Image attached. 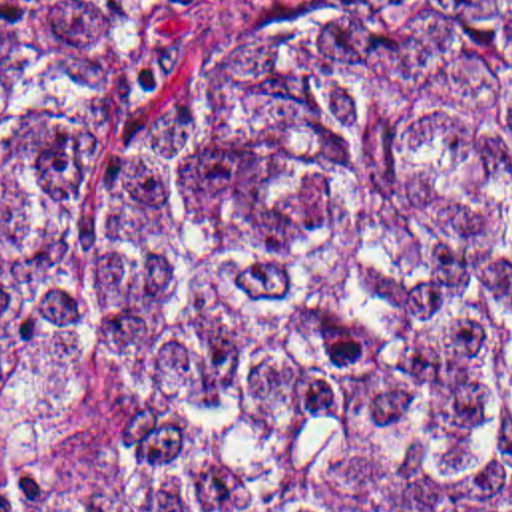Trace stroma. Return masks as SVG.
Returning <instances> with one entry per match:
<instances>
[{"instance_id": "35a3bbf8", "label": "stroma", "mask_w": 512, "mask_h": 512, "mask_svg": "<svg viewBox=\"0 0 512 512\" xmlns=\"http://www.w3.org/2000/svg\"><path fill=\"white\" fill-rule=\"evenodd\" d=\"M144 452V412L90 370H50L0 396V481H70Z\"/></svg>"}]
</instances>
